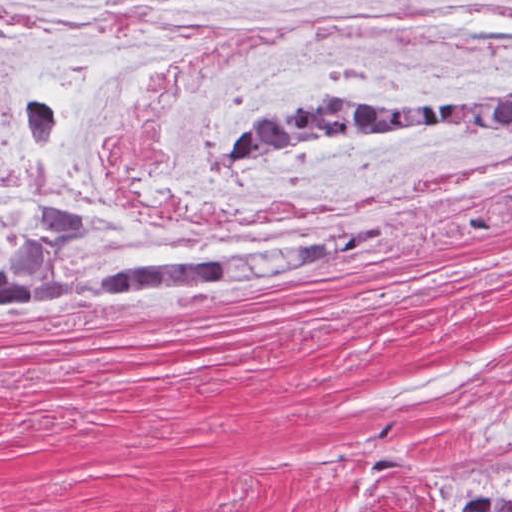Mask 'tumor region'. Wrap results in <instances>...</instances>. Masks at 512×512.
Listing matches in <instances>:
<instances>
[{
    "label": "tumor region",
    "instance_id": "1",
    "mask_svg": "<svg viewBox=\"0 0 512 512\" xmlns=\"http://www.w3.org/2000/svg\"><path fill=\"white\" fill-rule=\"evenodd\" d=\"M455 126L512 129V94L474 103L368 100L354 91H320L289 110L264 111L235 145L273 150L307 138ZM85 219L71 204L35 209L0 256V303L47 293L159 297L228 278H283L321 261H217L154 258L86 281H71L62 261Z\"/></svg>",
    "mask_w": 512,
    "mask_h": 512
}]
</instances>
